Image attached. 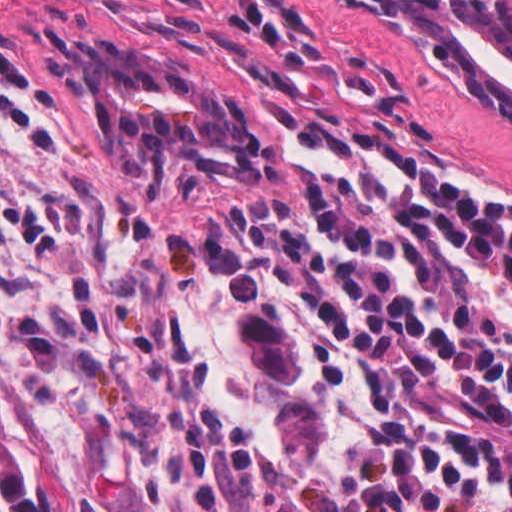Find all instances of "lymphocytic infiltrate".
<instances>
[{
    "label": "lymphocytic infiltrate",
    "instance_id": "1",
    "mask_svg": "<svg viewBox=\"0 0 512 512\" xmlns=\"http://www.w3.org/2000/svg\"><path fill=\"white\" fill-rule=\"evenodd\" d=\"M27 77L0 16V90ZM126 512H512V187L249 162L118 229Z\"/></svg>",
    "mask_w": 512,
    "mask_h": 512
}]
</instances>
